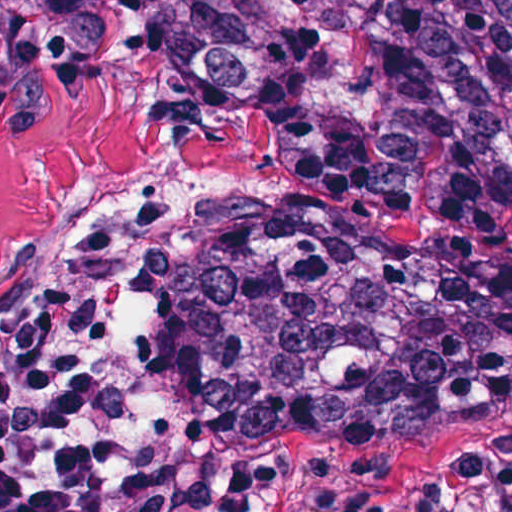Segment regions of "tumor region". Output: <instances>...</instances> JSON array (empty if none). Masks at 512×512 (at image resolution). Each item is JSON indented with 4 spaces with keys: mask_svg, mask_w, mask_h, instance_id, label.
<instances>
[{
    "mask_svg": "<svg viewBox=\"0 0 512 512\" xmlns=\"http://www.w3.org/2000/svg\"><path fill=\"white\" fill-rule=\"evenodd\" d=\"M142 51L277 138L297 192L410 223L512 204V0H1L0 80L46 97ZM121 274V238L0 272L19 326L71 264ZM512 404V253L290 225L233 287L182 296L150 349V413L195 457L422 435Z\"/></svg>",
    "mask_w": 512,
    "mask_h": 512,
    "instance_id": "e687c5a6",
    "label": "tumor region"
}]
</instances>
